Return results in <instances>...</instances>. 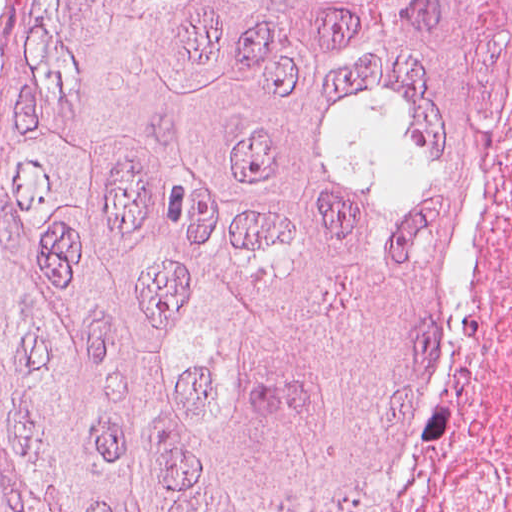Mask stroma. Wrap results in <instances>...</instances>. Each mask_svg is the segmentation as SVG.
Masks as SVG:
<instances>
[{"label": "stroma", "mask_w": 512, "mask_h": 512, "mask_svg": "<svg viewBox=\"0 0 512 512\" xmlns=\"http://www.w3.org/2000/svg\"><path fill=\"white\" fill-rule=\"evenodd\" d=\"M2 0H0V7ZM9 57V45L4 28L0 25V101L6 73V65Z\"/></svg>", "instance_id": "35a3bbf8"}]
</instances>
